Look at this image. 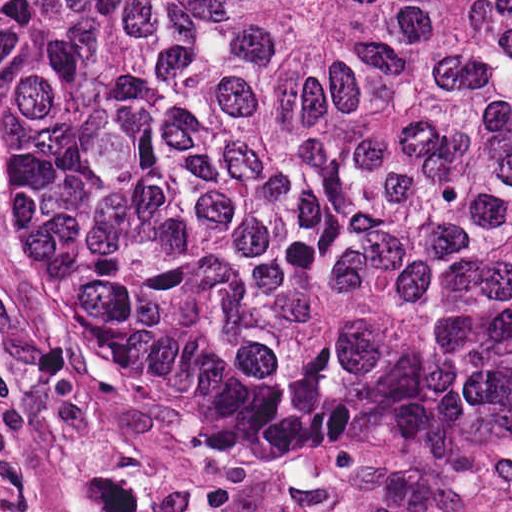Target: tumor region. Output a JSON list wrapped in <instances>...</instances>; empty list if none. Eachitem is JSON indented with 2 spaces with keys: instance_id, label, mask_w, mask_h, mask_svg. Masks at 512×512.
I'll list each match as a JSON object with an SVG mask.
<instances>
[{
  "instance_id": "1",
  "label": "tumor region",
  "mask_w": 512,
  "mask_h": 512,
  "mask_svg": "<svg viewBox=\"0 0 512 512\" xmlns=\"http://www.w3.org/2000/svg\"><path fill=\"white\" fill-rule=\"evenodd\" d=\"M0 172L144 392L512 457V0H0Z\"/></svg>"
}]
</instances>
